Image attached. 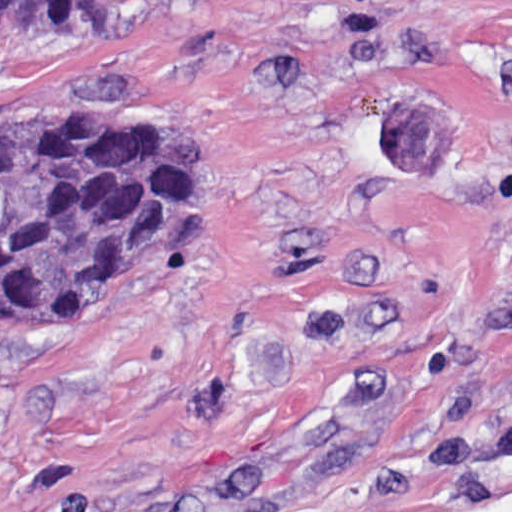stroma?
<instances>
[{"label":"stroma","instance_id":"obj_1","mask_svg":"<svg viewBox=\"0 0 512 512\" xmlns=\"http://www.w3.org/2000/svg\"><path fill=\"white\" fill-rule=\"evenodd\" d=\"M7 118L193 129L225 213L0 326V512H512V0H150Z\"/></svg>","mask_w":512,"mask_h":512}]
</instances>
